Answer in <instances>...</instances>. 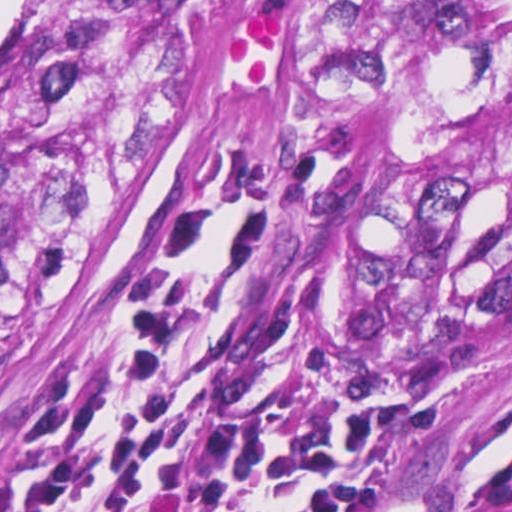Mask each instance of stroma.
<instances>
[{"label":"stroma","instance_id":"obj_1","mask_svg":"<svg viewBox=\"0 0 512 512\" xmlns=\"http://www.w3.org/2000/svg\"><path fill=\"white\" fill-rule=\"evenodd\" d=\"M0 31V45L35 4ZM257 151L318 174L327 190L282 208L261 252V336L269 360L374 406L378 496L372 512H459L512 442V321L462 349L422 341L389 307L369 234L321 152L289 121H249L106 223L62 292L0 342V483L33 400L64 378L101 375L121 342L114 306L137 282L182 203L206 209L207 263L238 156Z\"/></svg>","mask_w":512,"mask_h":512}]
</instances>
